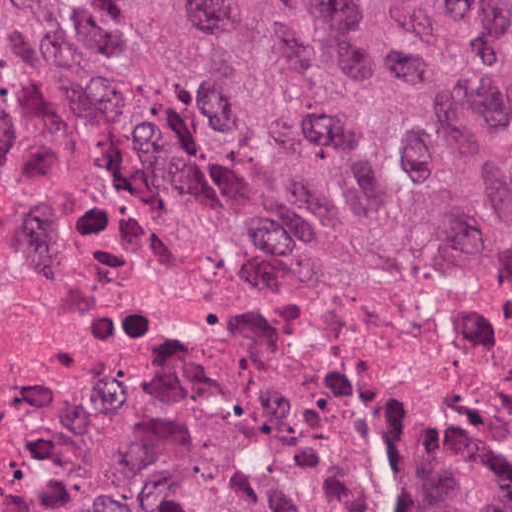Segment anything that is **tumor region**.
I'll list each match as a JSON object with an SVG mask.
<instances>
[{"mask_svg": "<svg viewBox=\"0 0 512 512\" xmlns=\"http://www.w3.org/2000/svg\"><path fill=\"white\" fill-rule=\"evenodd\" d=\"M4 81L106 168L441 266L512 252V1H0ZM0 512H349L284 456L178 436ZM392 512H448L395 480Z\"/></svg>", "mask_w": 512, "mask_h": 512, "instance_id": "tumor-region-1", "label": "tumor region"}]
</instances>
